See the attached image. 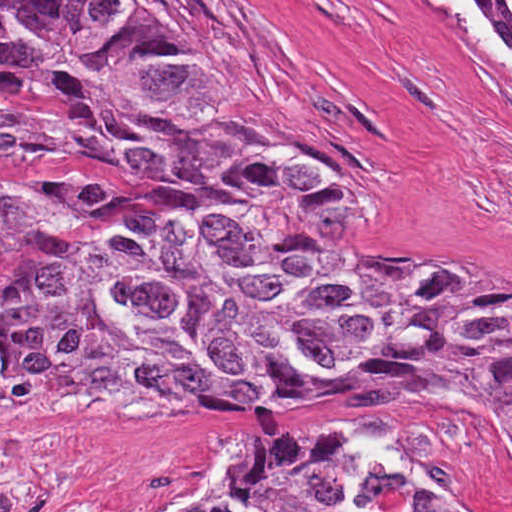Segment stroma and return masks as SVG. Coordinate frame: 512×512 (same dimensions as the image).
Wrapping results in <instances>:
<instances>
[{
  "label": "stroma",
  "mask_w": 512,
  "mask_h": 512,
  "mask_svg": "<svg viewBox=\"0 0 512 512\" xmlns=\"http://www.w3.org/2000/svg\"><path fill=\"white\" fill-rule=\"evenodd\" d=\"M512 32V12L487 0ZM212 58L232 110L310 174L283 185L298 233L394 273L512 276V73L465 48L430 0H159ZM0 153L96 181L116 209L19 232L108 261L205 169L57 146L0 123ZM25 271L0 201V347ZM46 512H178L251 450L339 425L459 512H512V454L485 417L433 405L322 403L247 422L39 421Z\"/></svg>",
  "instance_id": "1"
}]
</instances>
